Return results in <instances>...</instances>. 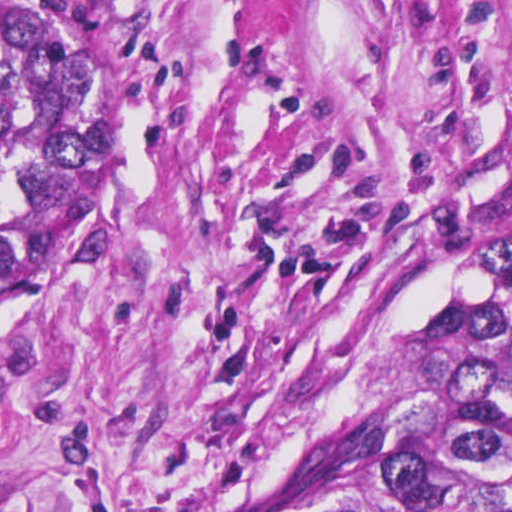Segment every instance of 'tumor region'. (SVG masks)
Listing matches in <instances>:
<instances>
[{"mask_svg":"<svg viewBox=\"0 0 512 512\" xmlns=\"http://www.w3.org/2000/svg\"><path fill=\"white\" fill-rule=\"evenodd\" d=\"M118 54L111 0H0V306L87 149ZM254 512H512V252L457 372L386 426H345Z\"/></svg>","mask_w":512,"mask_h":512,"instance_id":"1","label":"tumor region"}]
</instances>
